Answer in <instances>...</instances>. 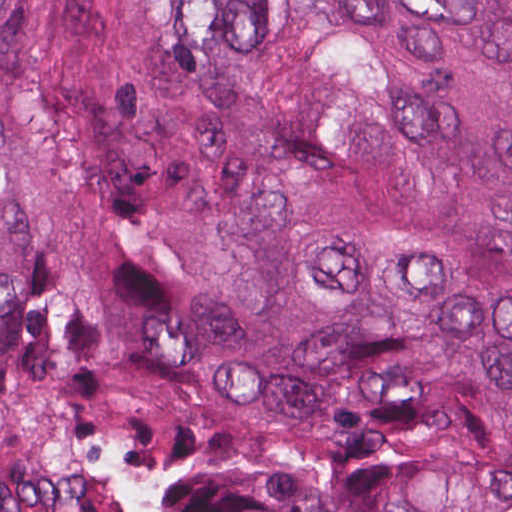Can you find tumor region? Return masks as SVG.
<instances>
[{
    "label": "tumor region",
    "mask_w": 512,
    "mask_h": 512,
    "mask_svg": "<svg viewBox=\"0 0 512 512\" xmlns=\"http://www.w3.org/2000/svg\"><path fill=\"white\" fill-rule=\"evenodd\" d=\"M0 512H512V0H0Z\"/></svg>",
    "instance_id": "tumor-region-1"
}]
</instances>
